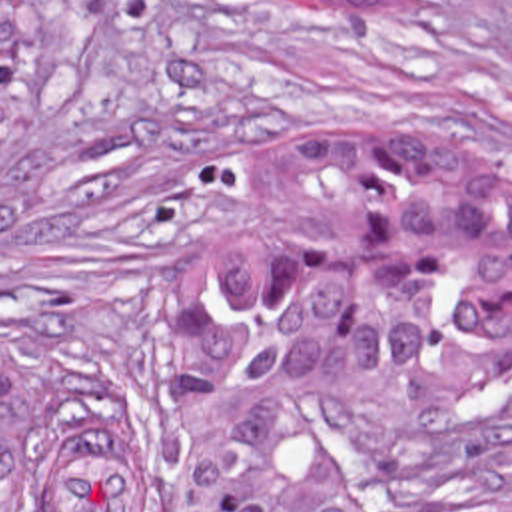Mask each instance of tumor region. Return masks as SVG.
Here are the masks:
<instances>
[{
    "instance_id": "tumor-region-1",
    "label": "tumor region",
    "mask_w": 512,
    "mask_h": 512,
    "mask_svg": "<svg viewBox=\"0 0 512 512\" xmlns=\"http://www.w3.org/2000/svg\"><path fill=\"white\" fill-rule=\"evenodd\" d=\"M37 8L0 0V139ZM259 203L265 241L223 251L177 317L175 512H512V439L361 431L375 391L512 387V197L484 143L454 125L301 131L261 157ZM0 512H145L143 425L0 347Z\"/></svg>"
}]
</instances>
